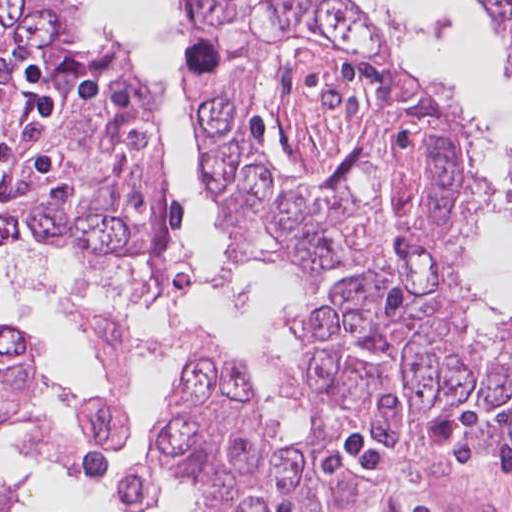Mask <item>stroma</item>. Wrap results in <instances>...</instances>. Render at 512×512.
I'll return each mask as SVG.
<instances>
[{
    "label": "stroma",
    "mask_w": 512,
    "mask_h": 512,
    "mask_svg": "<svg viewBox=\"0 0 512 512\" xmlns=\"http://www.w3.org/2000/svg\"><path fill=\"white\" fill-rule=\"evenodd\" d=\"M354 10L360 15L370 34L378 42L388 46L400 60L381 0L354 8ZM177 67L181 70L182 64ZM182 90L184 98L193 112L191 100L183 86ZM202 159L203 192L212 205L219 239L231 251L230 242L219 227L217 199L205 184L203 155ZM188 243L191 246L189 230ZM133 268L137 272V283L140 290L145 295L154 298L147 285L143 269ZM285 276L291 290L301 303V286L295 283L286 273ZM193 283L194 278L193 282L187 285L176 299L187 297L192 291ZM0 318L5 319L1 315ZM469 329L478 334L487 335L489 333L476 292L475 302L469 315ZM44 370L48 377L61 387L79 393H90L100 399L116 401L122 406L127 415L125 405L119 396L59 377L51 367L45 348ZM172 389L173 374L170 380L168 398ZM59 403L64 402L54 396H43L21 406L6 417L0 427V438L3 437L10 422L20 415L36 408ZM163 409L149 435L148 443ZM129 427L126 436L113 449L106 450L99 446L97 460L89 467L81 469L83 474L90 475L108 468L115 453L124 448ZM320 460L322 467L344 470L347 477L345 487L337 496L334 507L330 512H512V454H482L453 444L419 460H405L388 453L378 441L366 435L342 434L335 436L330 441L325 447ZM167 472L174 474L180 484L193 491L182 474L174 471ZM158 480L159 475H157L155 482L157 489ZM123 484L124 474L117 480L113 492V502L117 508L115 498ZM11 501L12 498L9 499L5 512H10ZM159 504L160 500L150 509L141 512H154ZM118 509L126 512L120 508Z\"/></svg>",
    "instance_id": "obj_1"
}]
</instances>
